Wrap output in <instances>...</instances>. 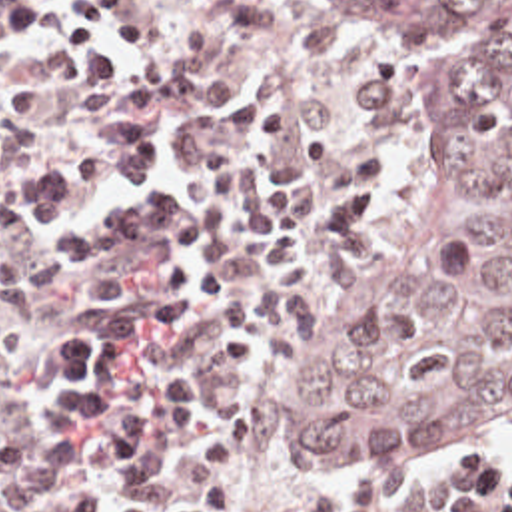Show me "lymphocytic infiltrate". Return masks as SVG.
I'll return each mask as SVG.
<instances>
[{
	"label": "lymphocytic infiltrate",
	"instance_id": "1",
	"mask_svg": "<svg viewBox=\"0 0 512 512\" xmlns=\"http://www.w3.org/2000/svg\"><path fill=\"white\" fill-rule=\"evenodd\" d=\"M137 0H1L0 27L53 25L73 83L127 79L133 49L149 45ZM101 35H107L117 45ZM79 177L49 165L17 193V219L43 241L47 263L87 277L103 313L59 323L45 385V421L97 438L121 512H237L255 446V419L221 415L195 454L185 494L163 510L169 482L151 450L207 423L211 379L193 367H159L145 339L167 329H207L225 375L261 367V319L253 293L231 277V179L227 149L201 153L181 185L171 145L147 117L127 115V159L103 135L79 143ZM155 267V277L143 271ZM494 464V508L512 512V468Z\"/></svg>",
	"mask_w": 512,
	"mask_h": 512
}]
</instances>
